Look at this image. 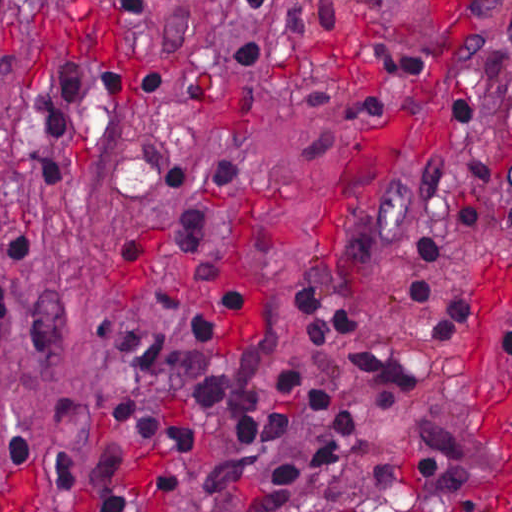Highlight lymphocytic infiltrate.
<instances>
[{
  "mask_svg": "<svg viewBox=\"0 0 512 512\" xmlns=\"http://www.w3.org/2000/svg\"><path fill=\"white\" fill-rule=\"evenodd\" d=\"M279 0H238L236 11L265 26L272 42L231 51L232 71L256 75L279 67L274 30ZM0 27L7 37V0H0ZM128 59L136 60V83L144 97L175 106L219 102L211 85L157 52L139 35ZM401 80L389 69L359 78L298 72L294 99L309 114L333 125L338 137L309 140L295 154L303 168H333L342 137L390 100ZM461 138L465 148L464 192L456 209L460 228L479 239L492 202V137L481 112L467 100L431 103ZM126 113L118 72L108 79L56 95L42 124L27 142L28 190L76 188L80 176L68 165L40 153L51 136H89L113 129ZM144 158L176 203L175 229L161 244L176 254H197L209 240L214 219L224 216L252 173L236 158L179 144H148ZM423 172L398 192L435 207L452 177V163L420 136ZM148 242L127 236L122 242L133 272ZM408 246L419 259L447 260L456 266L472 245L416 234ZM53 242L34 216L0 220V343L12 328L14 308L27 294L40 264L52 257ZM196 280L213 292L214 305L201 307L176 291L136 292V306L167 313L199 339H211L245 310L240 274L227 243L202 265ZM409 307L423 318L419 340L442 342L455 329L476 325L454 275L410 274L403 287ZM294 317L317 351H328L362 323L340 297L319 289L295 291ZM106 360L122 372V385L107 416L103 441L90 476L91 512H135V459L150 450L160 495L184 491L186 482L160 464L164 449L190 451L202 440L201 428L166 418L162 407L182 401L200 407L211 422L208 456L240 501L244 512H282L292 493L331 469L338 445L324 442L274 471L255 469L268 452L304 422L324 425L342 435L359 432V407L328 388L315 373L304 372L259 334L230 353H208L173 344L131 317L103 338ZM350 374L376 392H407L453 370L440 360L417 359L388 350L346 354ZM51 498L76 486L77 461L71 453L38 454Z\"/></svg>",
  "mask_w": 512,
  "mask_h": 512,
  "instance_id": "obj_1",
  "label": "lymphocytic infiltrate"
}]
</instances>
